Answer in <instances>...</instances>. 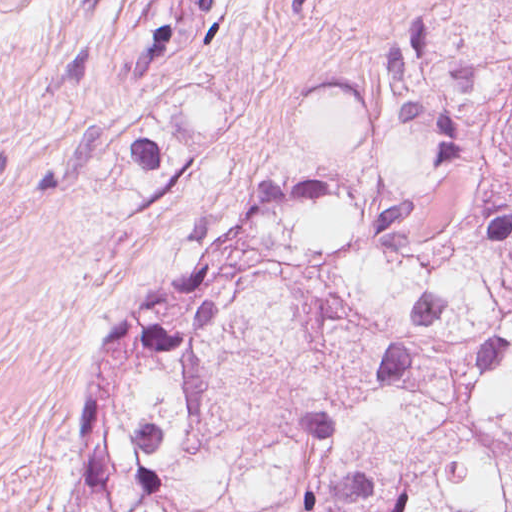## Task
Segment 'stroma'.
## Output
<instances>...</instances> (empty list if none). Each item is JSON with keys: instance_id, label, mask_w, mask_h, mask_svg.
<instances>
[{"instance_id": "35a3bbf8", "label": "stroma", "mask_w": 512, "mask_h": 512, "mask_svg": "<svg viewBox=\"0 0 512 512\" xmlns=\"http://www.w3.org/2000/svg\"><path fill=\"white\" fill-rule=\"evenodd\" d=\"M427 28L512 0H0V512H83L115 337L353 152Z\"/></svg>"}]
</instances>
